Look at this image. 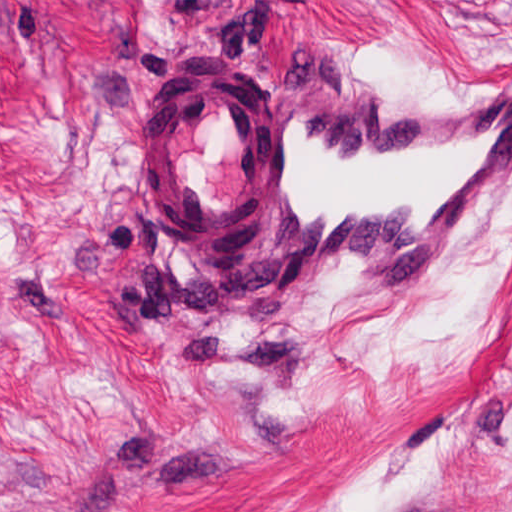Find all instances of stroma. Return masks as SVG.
<instances>
[{
    "label": "stroma",
    "instance_id": "35a3bbf8",
    "mask_svg": "<svg viewBox=\"0 0 512 512\" xmlns=\"http://www.w3.org/2000/svg\"><path fill=\"white\" fill-rule=\"evenodd\" d=\"M213 58L441 97L512 0H0V512H512V173L432 273L210 283L140 141Z\"/></svg>",
    "mask_w": 512,
    "mask_h": 512
}]
</instances>
